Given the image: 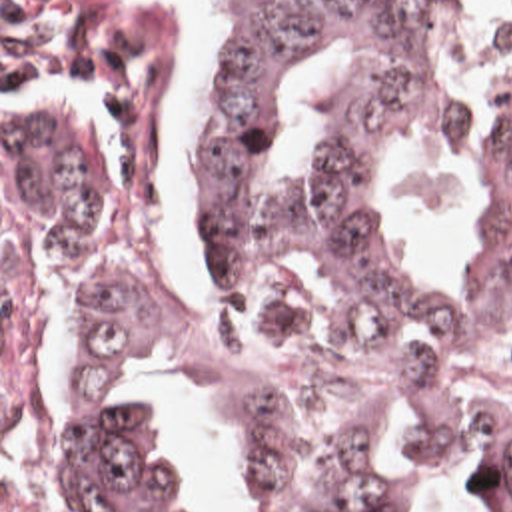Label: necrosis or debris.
Listing matches in <instances>:
<instances>
[{
    "label": "necrosis or debris",
    "mask_w": 512,
    "mask_h": 512,
    "mask_svg": "<svg viewBox=\"0 0 512 512\" xmlns=\"http://www.w3.org/2000/svg\"><path fill=\"white\" fill-rule=\"evenodd\" d=\"M2 512H84L64 463L28 455L2 467Z\"/></svg>",
    "instance_id": "necrosis-or-debris-1"
}]
</instances>
